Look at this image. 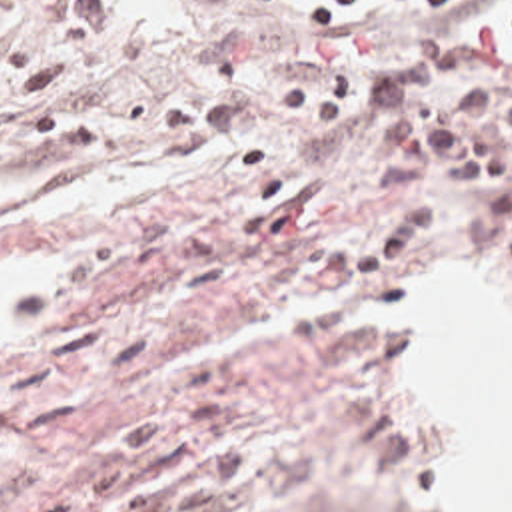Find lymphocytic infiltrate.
<instances>
[{
  "instance_id": "obj_1",
  "label": "lymphocytic infiltrate",
  "mask_w": 512,
  "mask_h": 512,
  "mask_svg": "<svg viewBox=\"0 0 512 512\" xmlns=\"http://www.w3.org/2000/svg\"><path fill=\"white\" fill-rule=\"evenodd\" d=\"M450 14L472 0H300L324 48L318 70L272 96L276 110L322 122L354 102H376V178L400 196L394 220L334 250L330 269L364 271L412 252L442 214L428 168L492 196L512 226V62L486 40L426 28L396 64H370L366 44L386 6Z\"/></svg>"
}]
</instances>
